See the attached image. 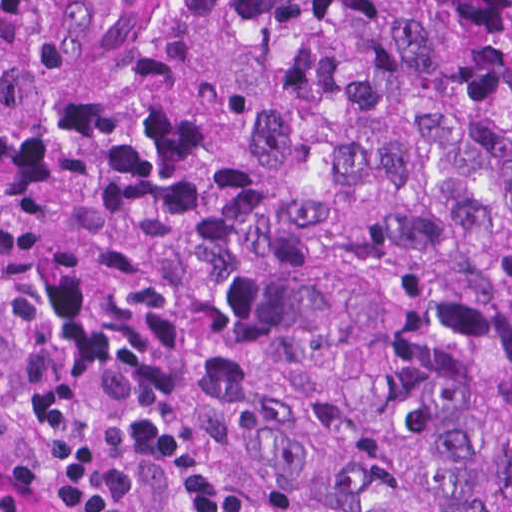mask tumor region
Listing matches in <instances>:
<instances>
[{
    "mask_svg": "<svg viewBox=\"0 0 512 512\" xmlns=\"http://www.w3.org/2000/svg\"><path fill=\"white\" fill-rule=\"evenodd\" d=\"M0 321L247 512H512V0H0Z\"/></svg>",
    "mask_w": 512,
    "mask_h": 512,
    "instance_id": "obj_1",
    "label": "tumor region"
}]
</instances>
